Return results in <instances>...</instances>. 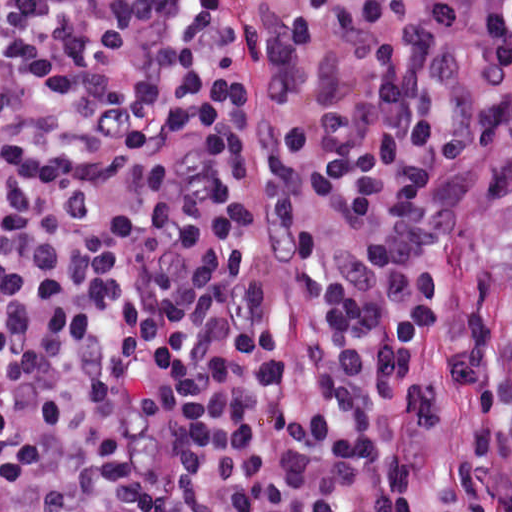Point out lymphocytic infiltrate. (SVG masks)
<instances>
[{
  "label": "lymphocytic infiltrate",
  "instance_id": "lymphocytic-infiltrate-1",
  "mask_svg": "<svg viewBox=\"0 0 512 512\" xmlns=\"http://www.w3.org/2000/svg\"><path fill=\"white\" fill-rule=\"evenodd\" d=\"M512 147V0H0V512H409L432 180ZM455 477L512 512L488 300Z\"/></svg>",
  "mask_w": 512,
  "mask_h": 512
}]
</instances>
